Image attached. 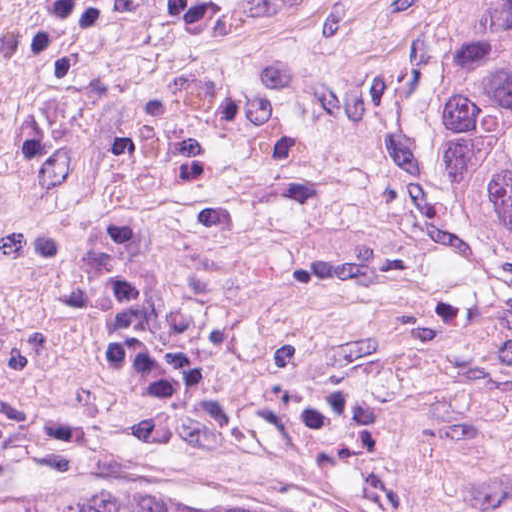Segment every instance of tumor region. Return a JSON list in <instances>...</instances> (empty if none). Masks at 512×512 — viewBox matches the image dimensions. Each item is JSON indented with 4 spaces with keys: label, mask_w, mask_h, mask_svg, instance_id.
<instances>
[{
    "label": "tumor region",
    "mask_w": 512,
    "mask_h": 512,
    "mask_svg": "<svg viewBox=\"0 0 512 512\" xmlns=\"http://www.w3.org/2000/svg\"><path fill=\"white\" fill-rule=\"evenodd\" d=\"M445 170L469 225L512 248V0H452ZM0 512H180L156 478L31 498Z\"/></svg>",
    "instance_id": "tumor-region-1"
}]
</instances>
